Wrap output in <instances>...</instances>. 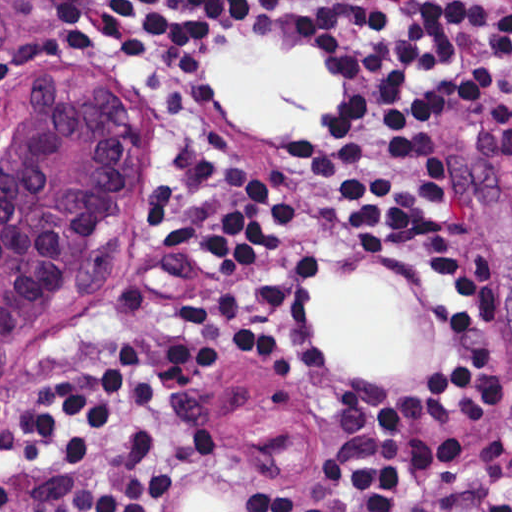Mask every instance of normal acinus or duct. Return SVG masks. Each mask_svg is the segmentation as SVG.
Listing matches in <instances>:
<instances>
[{"label": "normal acinus or duct", "mask_w": 512, "mask_h": 512, "mask_svg": "<svg viewBox=\"0 0 512 512\" xmlns=\"http://www.w3.org/2000/svg\"><path fill=\"white\" fill-rule=\"evenodd\" d=\"M76 85L23 103L0 145V342L32 326L71 282L127 166L116 106Z\"/></svg>", "instance_id": "1"}]
</instances>
